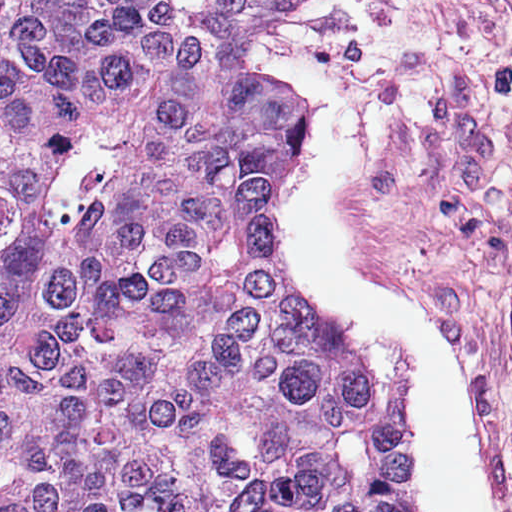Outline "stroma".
Instances as JSON below:
<instances>
[{
	"label": "stroma",
	"instance_id": "1",
	"mask_svg": "<svg viewBox=\"0 0 512 512\" xmlns=\"http://www.w3.org/2000/svg\"><path fill=\"white\" fill-rule=\"evenodd\" d=\"M314 45L361 135L345 215L455 366L512 512V0H333Z\"/></svg>",
	"mask_w": 512,
	"mask_h": 512
}]
</instances>
